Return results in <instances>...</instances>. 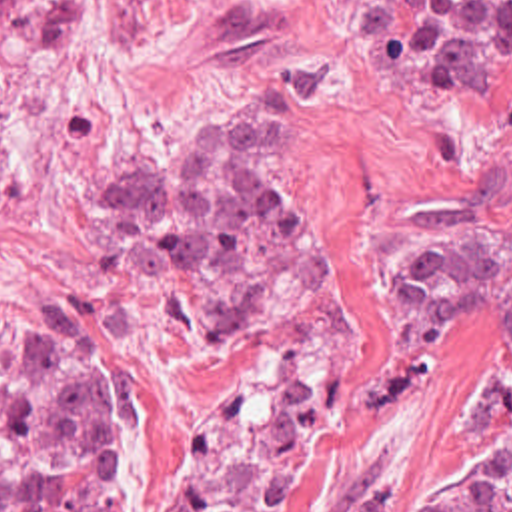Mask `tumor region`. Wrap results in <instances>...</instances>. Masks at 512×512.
Wrapping results in <instances>:
<instances>
[{"label": "tumor region", "instance_id": "obj_1", "mask_svg": "<svg viewBox=\"0 0 512 512\" xmlns=\"http://www.w3.org/2000/svg\"><path fill=\"white\" fill-rule=\"evenodd\" d=\"M0 28L39 54L83 36V0H0ZM373 44L455 96L512 100V0H373ZM8 141L0 137V195ZM115 273L157 277L203 341L291 303L315 267V225L289 173V112L227 102L127 167L105 199ZM393 297L441 337L512 345V225L439 215L399 253ZM512 459L385 473L343 512H512ZM0 512H129V405L81 349L4 353Z\"/></svg>", "mask_w": 512, "mask_h": 512}]
</instances>
